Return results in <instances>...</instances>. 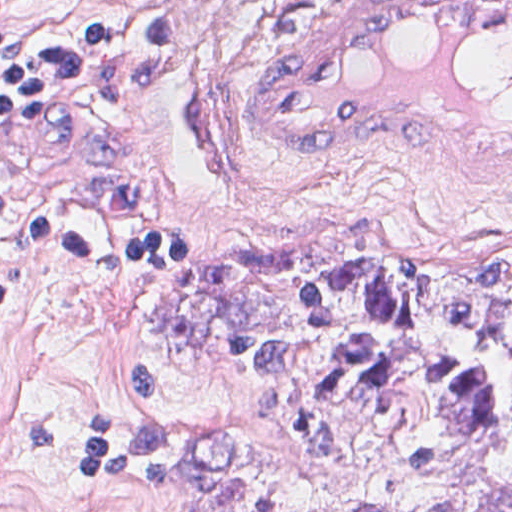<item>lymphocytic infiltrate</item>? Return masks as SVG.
<instances>
[{
  "label": "lymphocytic infiltrate",
  "mask_w": 512,
  "mask_h": 512,
  "mask_svg": "<svg viewBox=\"0 0 512 512\" xmlns=\"http://www.w3.org/2000/svg\"><path fill=\"white\" fill-rule=\"evenodd\" d=\"M175 37L145 2L77 14L69 1H0V131L71 103L152 61ZM0 238L58 264L141 269L185 264V232L98 209L0 172Z\"/></svg>",
  "instance_id": "1"
}]
</instances>
